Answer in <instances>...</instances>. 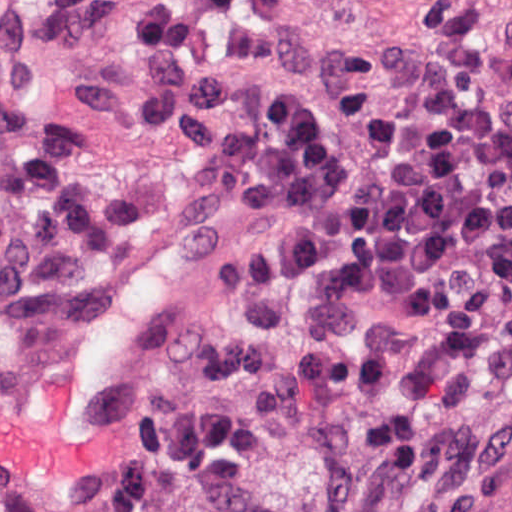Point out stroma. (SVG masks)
Instances as JSON below:
<instances>
[{
	"mask_svg": "<svg viewBox=\"0 0 512 512\" xmlns=\"http://www.w3.org/2000/svg\"><path fill=\"white\" fill-rule=\"evenodd\" d=\"M169 13L180 57L199 71L234 83L240 111L248 120H265L269 100L286 89H299L328 107L343 87H366L384 93L395 107L413 106L391 73L381 67L326 71L302 64H267L243 34L241 0H178ZM37 80L45 101L59 114L82 88L110 83L141 109L144 77L137 33L63 42L46 49L37 54ZM302 229L291 217L278 220L245 209L225 211L214 202V238L204 289L161 327L148 348L135 383L122 450L166 404L189 401L197 394L213 336L234 324L240 314L226 292L224 274L231 267H243L262 244L300 236ZM299 318L311 331L337 341L378 336L423 340L455 385L486 408L488 448L464 484L434 489L430 481L395 483L382 468H373L356 512H512V382L490 377L435 334L428 322L382 294L312 292L300 300ZM44 321L15 327L6 322L0 308V361L20 352ZM265 488L279 512H313L305 446L293 431L276 438L267 455ZM104 498L105 483L84 505H42L0 496V512H86L101 506ZM149 501L152 512H186L177 484L155 488Z\"/></svg>",
	"mask_w": 512,
	"mask_h": 512,
	"instance_id": "35a3bbf8",
	"label": "stroma"
}]
</instances>
